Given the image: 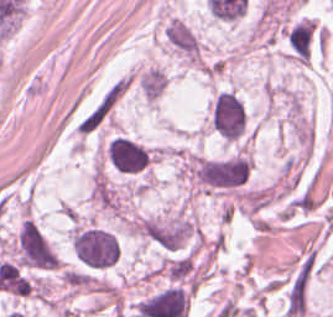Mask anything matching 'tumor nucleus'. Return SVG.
<instances>
[{"label":"tumor nucleus","instance_id":"tumor-nucleus-1","mask_svg":"<svg viewBox=\"0 0 333 317\" xmlns=\"http://www.w3.org/2000/svg\"><path fill=\"white\" fill-rule=\"evenodd\" d=\"M211 127L221 136L235 140L244 135L246 109L233 90H219L211 103Z\"/></svg>","mask_w":333,"mask_h":317},{"label":"tumor nucleus","instance_id":"tumor-nucleus-2","mask_svg":"<svg viewBox=\"0 0 333 317\" xmlns=\"http://www.w3.org/2000/svg\"><path fill=\"white\" fill-rule=\"evenodd\" d=\"M152 150L127 136L114 135L105 146V157L118 172L141 173L149 165Z\"/></svg>","mask_w":333,"mask_h":317},{"label":"tumor nucleus","instance_id":"tumor-nucleus-3","mask_svg":"<svg viewBox=\"0 0 333 317\" xmlns=\"http://www.w3.org/2000/svg\"><path fill=\"white\" fill-rule=\"evenodd\" d=\"M166 80L167 75L158 67H153L143 75L140 84L142 96L150 101L156 99L163 92Z\"/></svg>","mask_w":333,"mask_h":317}]
</instances>
